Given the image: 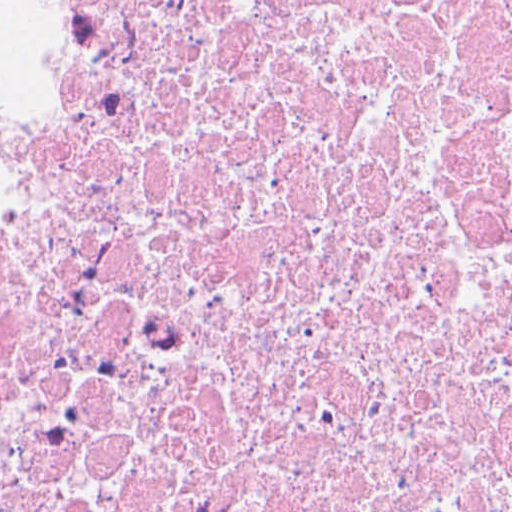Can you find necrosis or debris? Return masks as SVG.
Listing matches in <instances>:
<instances>
[{
  "mask_svg": "<svg viewBox=\"0 0 512 512\" xmlns=\"http://www.w3.org/2000/svg\"><path fill=\"white\" fill-rule=\"evenodd\" d=\"M0 512H512V0H22Z\"/></svg>",
  "mask_w": 512,
  "mask_h": 512,
  "instance_id": "obj_1",
  "label": "necrosis or debris"
}]
</instances>
